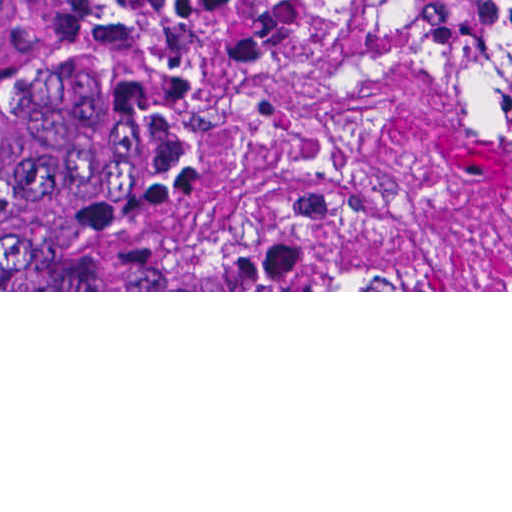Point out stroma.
<instances>
[{
    "mask_svg": "<svg viewBox=\"0 0 512 512\" xmlns=\"http://www.w3.org/2000/svg\"><path fill=\"white\" fill-rule=\"evenodd\" d=\"M185 1L237 108L221 171L322 161L439 255L447 290H151L153 243L185 206L142 212V290L0 292H512L510 73L370 0Z\"/></svg>",
    "mask_w": 512,
    "mask_h": 512,
    "instance_id": "1",
    "label": "stroma"
}]
</instances>
